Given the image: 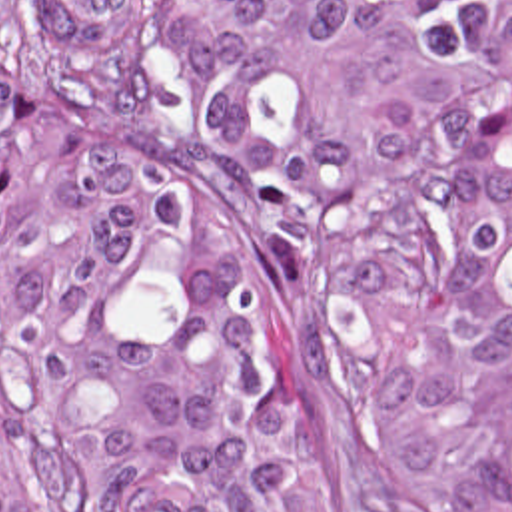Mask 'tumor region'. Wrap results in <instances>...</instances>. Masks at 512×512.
I'll use <instances>...</instances> for the list:
<instances>
[{"label": "tumor region", "instance_id": "obj_1", "mask_svg": "<svg viewBox=\"0 0 512 512\" xmlns=\"http://www.w3.org/2000/svg\"><path fill=\"white\" fill-rule=\"evenodd\" d=\"M143 15L0 0L1 400L65 512H337L289 320L135 119ZM175 37L193 131L333 280L416 510L512 512V0H175Z\"/></svg>", "mask_w": 512, "mask_h": 512}]
</instances>
